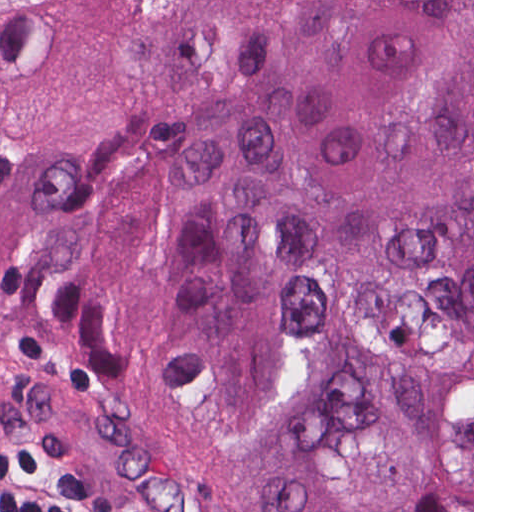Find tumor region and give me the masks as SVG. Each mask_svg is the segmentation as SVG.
<instances>
[{
  "mask_svg": "<svg viewBox=\"0 0 512 512\" xmlns=\"http://www.w3.org/2000/svg\"><path fill=\"white\" fill-rule=\"evenodd\" d=\"M0 342L252 512H472V0H77L0 89Z\"/></svg>",
  "mask_w": 512,
  "mask_h": 512,
  "instance_id": "tumor-region-1",
  "label": "tumor region"
}]
</instances>
